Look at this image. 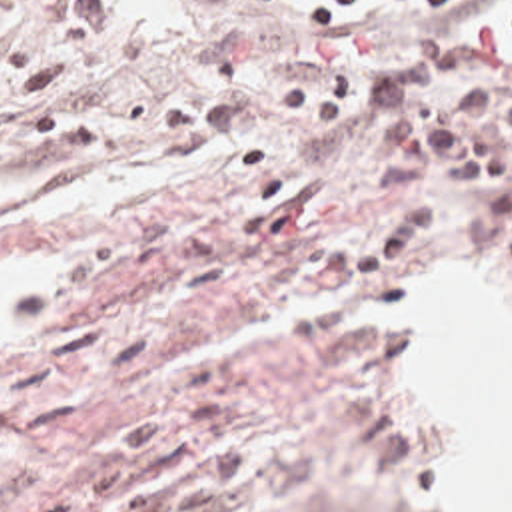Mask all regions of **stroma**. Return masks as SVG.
Returning a JSON list of instances; mask_svg holds the SVG:
<instances>
[{"mask_svg": "<svg viewBox=\"0 0 512 512\" xmlns=\"http://www.w3.org/2000/svg\"><path fill=\"white\" fill-rule=\"evenodd\" d=\"M426 28L512 62V0L394 2L366 58ZM322 54L300 0H0V176L152 170L146 194L0 214V259L44 263L28 309H0V512L452 511L410 471L448 409L358 311L444 256L512 265V226L432 166L444 210L412 252L322 265L400 210L376 102L274 108Z\"/></svg>", "mask_w": 512, "mask_h": 512, "instance_id": "35a3bbf8", "label": "stroma"}]
</instances>
